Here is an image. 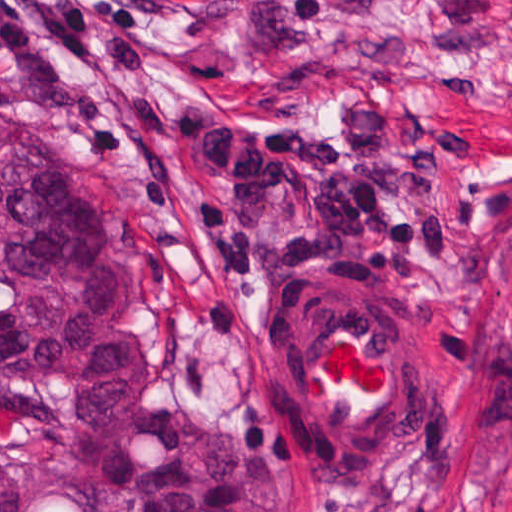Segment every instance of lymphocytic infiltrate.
I'll return each mask as SVG.
<instances>
[{"label":"lymphocytic infiltrate","mask_w":512,"mask_h":512,"mask_svg":"<svg viewBox=\"0 0 512 512\" xmlns=\"http://www.w3.org/2000/svg\"><path fill=\"white\" fill-rule=\"evenodd\" d=\"M232 2L238 0H200ZM159 0H0V51L48 49L62 67L101 56L88 35L132 37ZM162 118L208 169L193 216L217 253L206 301L176 332L182 397H205L231 374L267 291L292 277H338L400 297L424 260L452 256L467 234L436 196L443 149L467 140L440 120L417 147L385 97L348 101L338 122L301 124L247 105H170Z\"/></svg>","instance_id":"obj_1"}]
</instances>
